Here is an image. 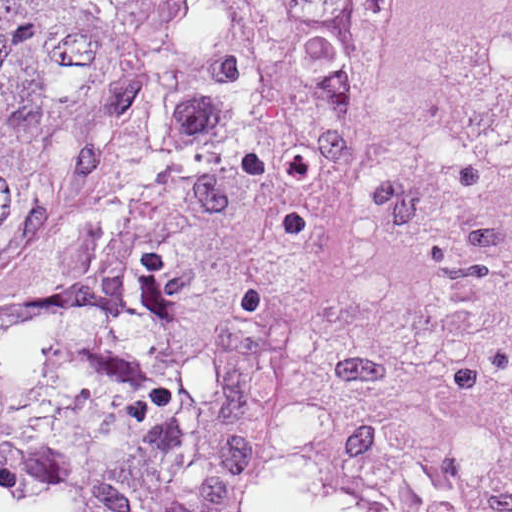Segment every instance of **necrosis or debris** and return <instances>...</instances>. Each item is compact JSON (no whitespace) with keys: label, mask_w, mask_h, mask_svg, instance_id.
<instances>
[{"label":"necrosis or debris","mask_w":512,"mask_h":512,"mask_svg":"<svg viewBox=\"0 0 512 512\" xmlns=\"http://www.w3.org/2000/svg\"><path fill=\"white\" fill-rule=\"evenodd\" d=\"M266 512H512V0H388Z\"/></svg>","instance_id":"1"}]
</instances>
